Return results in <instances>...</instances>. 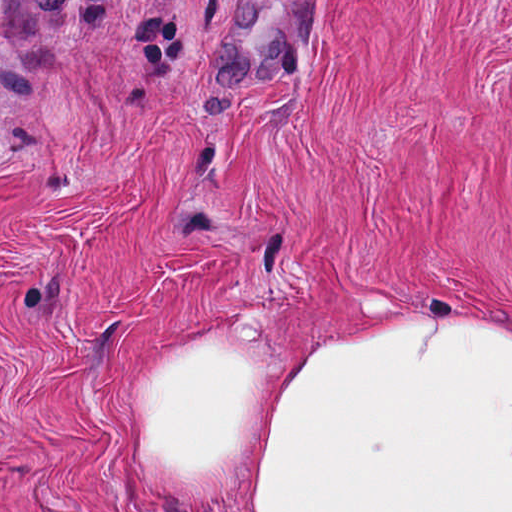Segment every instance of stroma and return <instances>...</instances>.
Returning a JSON list of instances; mask_svg holds the SVG:
<instances>
[{
    "instance_id": "obj_1",
    "label": "stroma",
    "mask_w": 512,
    "mask_h": 512,
    "mask_svg": "<svg viewBox=\"0 0 512 512\" xmlns=\"http://www.w3.org/2000/svg\"><path fill=\"white\" fill-rule=\"evenodd\" d=\"M236 1H306L273 81L210 77ZM411 314L512 338V0H0V512H175L124 447L155 340Z\"/></svg>"
}]
</instances>
